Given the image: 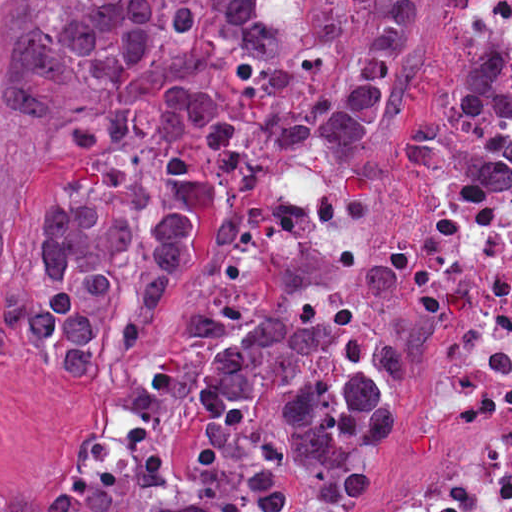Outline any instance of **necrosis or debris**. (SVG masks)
<instances>
[{"mask_svg":"<svg viewBox=\"0 0 512 512\" xmlns=\"http://www.w3.org/2000/svg\"><path fill=\"white\" fill-rule=\"evenodd\" d=\"M512 34V0H457ZM392 268L434 331L447 377L475 408V448L432 485L362 512H512V201L447 191L392 226Z\"/></svg>","mask_w":512,"mask_h":512,"instance_id":"1","label":"necrosis or debris"}]
</instances>
